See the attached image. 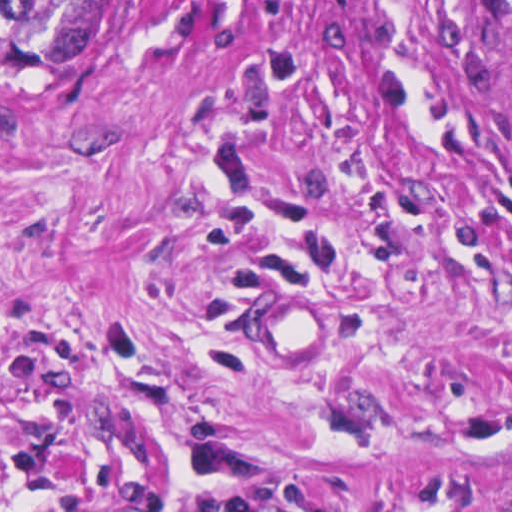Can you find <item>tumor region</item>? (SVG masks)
Segmentation results:
<instances>
[{
	"mask_svg": "<svg viewBox=\"0 0 512 512\" xmlns=\"http://www.w3.org/2000/svg\"><path fill=\"white\" fill-rule=\"evenodd\" d=\"M118 0H1V68L61 69L84 62L106 36ZM512 57V0H480Z\"/></svg>",
	"mask_w": 512,
	"mask_h": 512,
	"instance_id": "obj_1",
	"label": "tumor region"
}]
</instances>
